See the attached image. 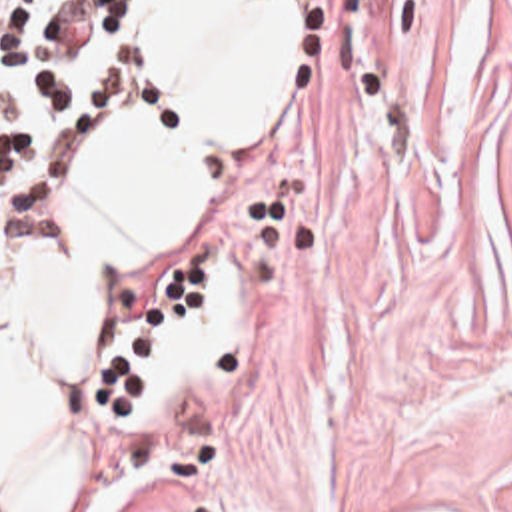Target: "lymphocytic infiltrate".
I'll list each match as a JSON object with an SVG mask.
<instances>
[{
	"label": "lymphocytic infiltrate",
	"instance_id": "obj_1",
	"mask_svg": "<svg viewBox=\"0 0 512 512\" xmlns=\"http://www.w3.org/2000/svg\"><path fill=\"white\" fill-rule=\"evenodd\" d=\"M162 100V0H0V216L54 226L68 148Z\"/></svg>",
	"mask_w": 512,
	"mask_h": 512
}]
</instances>
